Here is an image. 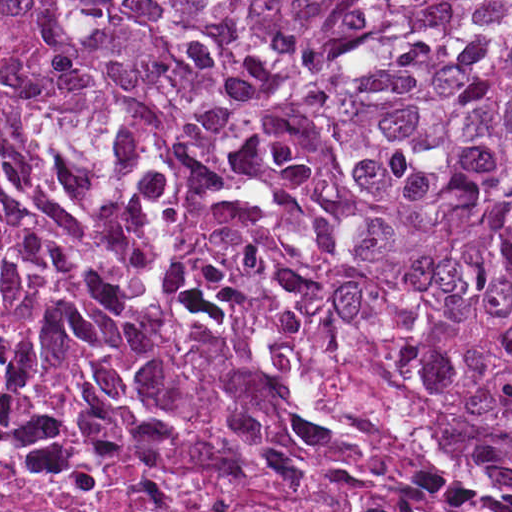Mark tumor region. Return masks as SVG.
I'll return each instance as SVG.
<instances>
[{"label": "tumor region", "mask_w": 512, "mask_h": 512, "mask_svg": "<svg viewBox=\"0 0 512 512\" xmlns=\"http://www.w3.org/2000/svg\"><path fill=\"white\" fill-rule=\"evenodd\" d=\"M171 226L512 430V0H0Z\"/></svg>", "instance_id": "tumor-region-1"}]
</instances>
